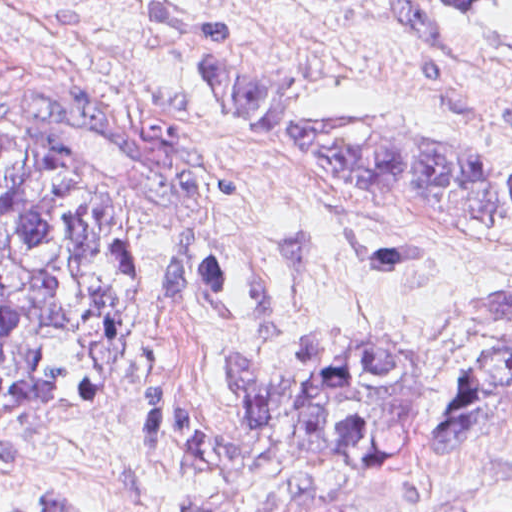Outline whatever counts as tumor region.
I'll use <instances>...</instances> for the list:
<instances>
[{"label": "tumor region", "mask_w": 512, "mask_h": 512, "mask_svg": "<svg viewBox=\"0 0 512 512\" xmlns=\"http://www.w3.org/2000/svg\"><path fill=\"white\" fill-rule=\"evenodd\" d=\"M399 1L490 35L512 54V19L494 17L493 0ZM146 8L193 39L207 90L288 160L361 197L454 223L512 225L511 161L453 134L376 113H313L259 75L224 23L228 16L162 0ZM485 301L512 322V297ZM132 322L120 214L40 153L0 136V408L106 400L124 378ZM235 361L237 411L226 429L194 421L165 382L150 387L145 425L154 446L170 452L174 476L282 441L291 452L455 446L478 421L512 418V342L468 370L436 418L412 366L393 346L348 354L323 340H301L292 384H272L246 359Z\"/></svg>", "instance_id": "1"}]
</instances>
